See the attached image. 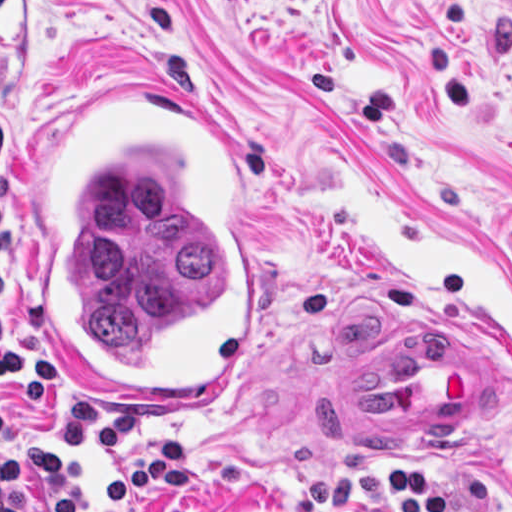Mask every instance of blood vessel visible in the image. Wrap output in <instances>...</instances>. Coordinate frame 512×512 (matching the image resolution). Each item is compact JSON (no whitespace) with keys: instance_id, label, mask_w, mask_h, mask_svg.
Listing matches in <instances>:
<instances>
[{"instance_id":"obj_1","label":"blood vessel","mask_w":512,"mask_h":512,"mask_svg":"<svg viewBox=\"0 0 512 512\" xmlns=\"http://www.w3.org/2000/svg\"><path fill=\"white\" fill-rule=\"evenodd\" d=\"M184 95L226 129L211 108ZM39 220L37 194L22 289V319L29 338L42 353L33 330V250ZM487 410L488 353L447 335L391 345L330 382L321 405L323 422L333 439L352 454H414L479 427Z\"/></svg>"}]
</instances>
